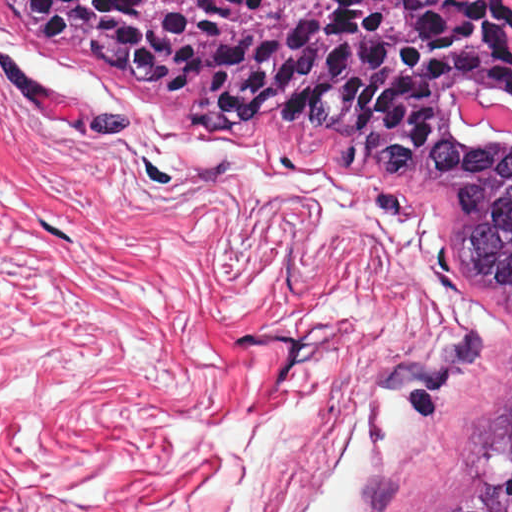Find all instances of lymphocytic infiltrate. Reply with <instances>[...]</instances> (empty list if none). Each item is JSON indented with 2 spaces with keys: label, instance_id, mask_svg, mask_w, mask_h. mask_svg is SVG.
I'll return each instance as SVG.
<instances>
[{
  "label": "lymphocytic infiltrate",
  "instance_id": "1",
  "mask_svg": "<svg viewBox=\"0 0 512 512\" xmlns=\"http://www.w3.org/2000/svg\"><path fill=\"white\" fill-rule=\"evenodd\" d=\"M25 21L27 22V24L29 25V28L39 34H43V35H47V36H51L49 33H47L46 31H44L43 29H41L40 27L36 26L35 24H33L32 22H30L27 18H25ZM53 37V36H52ZM455 69H456V63H455V59L451 58L449 59L448 61H446L445 63H443L442 65H440V69H439V75H438V83L442 82L443 80H445L446 78H448L449 76H451L454 72H455ZM506 91V90H505ZM509 92L510 94H512V91H507ZM219 120V119H218ZM219 122L227 129H231V130H235V129H239L238 127L236 126H233L231 124H228V123H225L221 120H219ZM434 131H435V121L433 122V128H432V138H431V144L433 142V139H434ZM430 148V147H429ZM429 148H427L425 151H422L421 153H418V154H423L425 153Z\"/></svg>",
  "mask_w": 512,
  "mask_h": 512
}]
</instances>
